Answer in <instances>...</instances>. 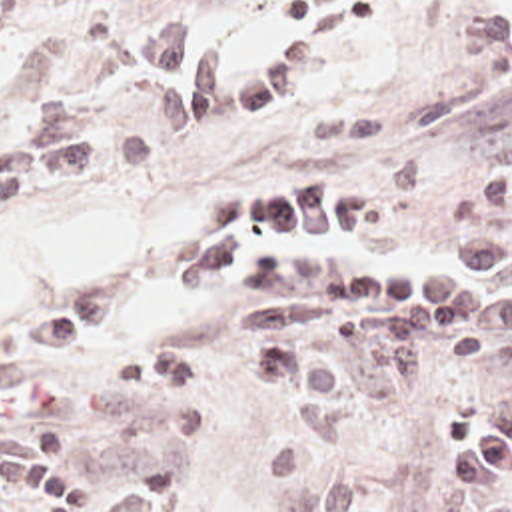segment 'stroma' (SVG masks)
<instances>
[{"mask_svg":"<svg viewBox=\"0 0 512 512\" xmlns=\"http://www.w3.org/2000/svg\"><path fill=\"white\" fill-rule=\"evenodd\" d=\"M306 0H190L204 40L266 62L302 34L282 8ZM169 16L159 2L0 0V150L21 144L51 102L79 108L89 134H135L151 160L77 188L49 184L9 208L17 228L79 206H117L169 190L192 194L186 234L141 240L83 302L117 328L39 380L77 386L107 360L181 354L194 390L147 396L91 412L73 434L69 472L115 474L143 462H190L198 482L161 512H282L318 480L264 474L260 454L286 424V402L238 378L240 354L280 336L330 340L334 326L246 330L240 294L183 292L177 264L198 254L218 200L236 190L330 184L356 190L382 212L376 228L332 236H256L324 252L406 260L452 272L484 238L512 240V0H376L350 40L308 62L278 104L238 122L163 128L145 38ZM61 312V314H65ZM21 334L0 340V366ZM512 386L506 370L442 362L400 400L364 414L358 458L392 512H512V482L444 492L430 476L442 450L430 428L466 404Z\"/></svg>","mask_w":512,"mask_h":512,"instance_id":"1","label":"stroma"}]
</instances>
